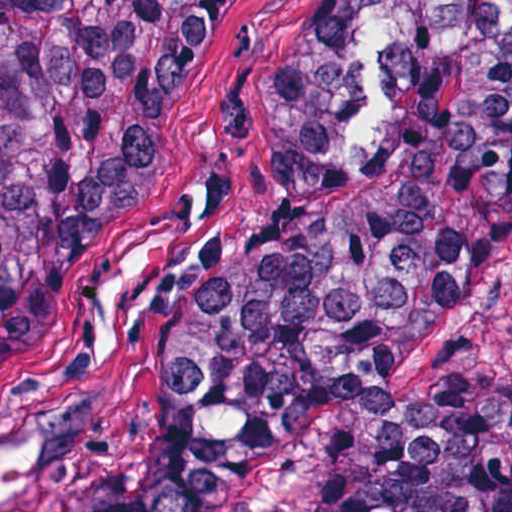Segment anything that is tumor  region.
Returning a JSON list of instances; mask_svg holds the SVG:
<instances>
[{"instance_id":"e687c5a6","label":"tumor region","mask_w":512,"mask_h":512,"mask_svg":"<svg viewBox=\"0 0 512 512\" xmlns=\"http://www.w3.org/2000/svg\"><path fill=\"white\" fill-rule=\"evenodd\" d=\"M221 0L0 7V350L68 269ZM271 224L88 469L0 512H211L323 418L398 404L417 333L512 244V0H357L274 107ZM312 512H512V379L448 375Z\"/></svg>"}]
</instances>
